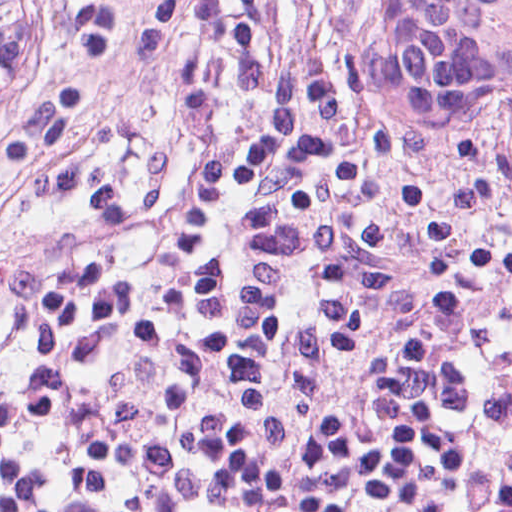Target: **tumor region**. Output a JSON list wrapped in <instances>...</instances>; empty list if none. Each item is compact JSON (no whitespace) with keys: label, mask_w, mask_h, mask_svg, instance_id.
I'll use <instances>...</instances> for the list:
<instances>
[{"label":"tumor region","mask_w":512,"mask_h":512,"mask_svg":"<svg viewBox=\"0 0 512 512\" xmlns=\"http://www.w3.org/2000/svg\"><path fill=\"white\" fill-rule=\"evenodd\" d=\"M365 54L402 102L512 147V0H370Z\"/></svg>","instance_id":"e687c5a6"}]
</instances>
